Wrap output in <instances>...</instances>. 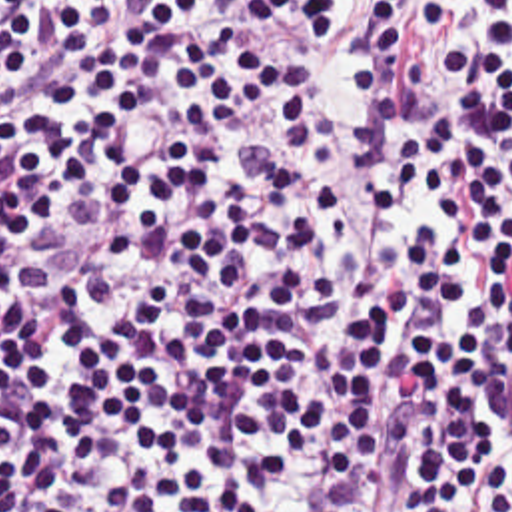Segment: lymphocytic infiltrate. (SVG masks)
I'll use <instances>...</instances> for the list:
<instances>
[{
	"instance_id": "f902f5d3",
	"label": "lymphocytic infiltrate",
	"mask_w": 512,
	"mask_h": 512,
	"mask_svg": "<svg viewBox=\"0 0 512 512\" xmlns=\"http://www.w3.org/2000/svg\"><path fill=\"white\" fill-rule=\"evenodd\" d=\"M0 512H512V0H0Z\"/></svg>"
}]
</instances>
